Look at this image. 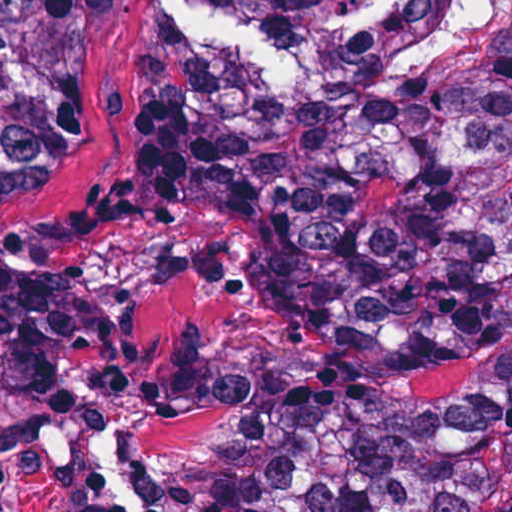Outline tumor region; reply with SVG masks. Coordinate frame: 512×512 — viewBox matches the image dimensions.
<instances>
[{
    "label": "tumor region",
    "instance_id": "tumor-region-1",
    "mask_svg": "<svg viewBox=\"0 0 512 512\" xmlns=\"http://www.w3.org/2000/svg\"><path fill=\"white\" fill-rule=\"evenodd\" d=\"M124 0H0V204L85 135ZM312 75L165 58L126 194L194 183L249 212L307 325L239 512H512V0H331ZM107 377V309L0 253V404ZM186 362L173 394L193 402Z\"/></svg>",
    "mask_w": 512,
    "mask_h": 512
}]
</instances>
